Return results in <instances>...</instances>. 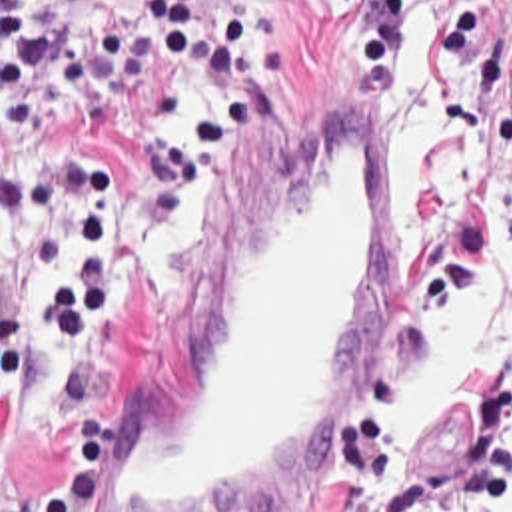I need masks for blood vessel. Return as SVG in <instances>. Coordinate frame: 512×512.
I'll list each match as a JSON object with an SVG mask.
<instances>
[{"label": "blood vessel", "instance_id": "obj_1", "mask_svg": "<svg viewBox=\"0 0 512 512\" xmlns=\"http://www.w3.org/2000/svg\"><path fill=\"white\" fill-rule=\"evenodd\" d=\"M197 300L145 412L94 463L82 512H265L351 428L387 336L393 146L345 92Z\"/></svg>", "mask_w": 512, "mask_h": 512}]
</instances>
